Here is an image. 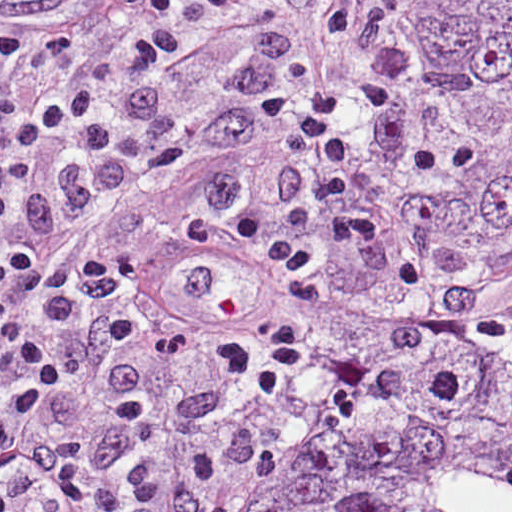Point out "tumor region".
Listing matches in <instances>:
<instances>
[{"instance_id": "tumor-region-1", "label": "tumor region", "mask_w": 512, "mask_h": 512, "mask_svg": "<svg viewBox=\"0 0 512 512\" xmlns=\"http://www.w3.org/2000/svg\"><path fill=\"white\" fill-rule=\"evenodd\" d=\"M0 512H512V0H257L99 100L0 270Z\"/></svg>"}]
</instances>
